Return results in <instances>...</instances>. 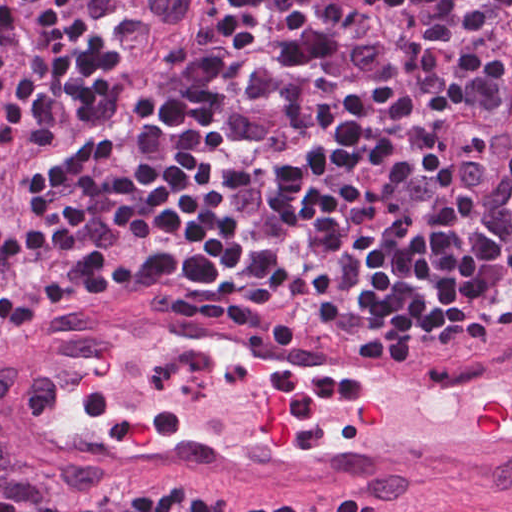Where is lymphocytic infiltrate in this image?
<instances>
[{"label": "lymphocytic infiltrate", "instance_id": "obj_1", "mask_svg": "<svg viewBox=\"0 0 512 512\" xmlns=\"http://www.w3.org/2000/svg\"><path fill=\"white\" fill-rule=\"evenodd\" d=\"M112 286L460 322L444 342L489 323L512 296V0H104L0 116V324ZM61 512L326 511L134 484Z\"/></svg>", "mask_w": 512, "mask_h": 512}]
</instances>
